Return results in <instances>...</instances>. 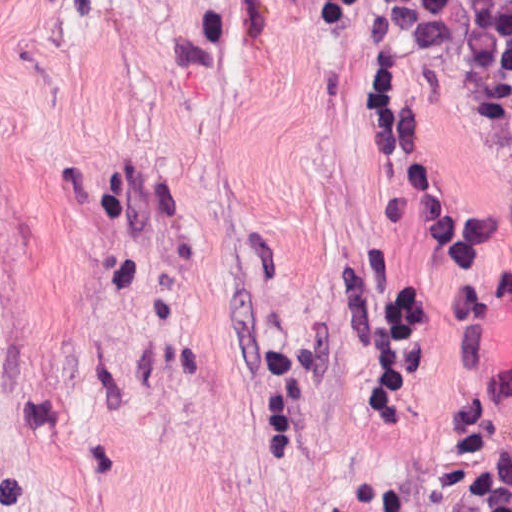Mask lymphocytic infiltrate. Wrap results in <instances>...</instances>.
Masks as SVG:
<instances>
[{"label": "lymphocytic infiltrate", "instance_id": "lymphocytic-infiltrate-1", "mask_svg": "<svg viewBox=\"0 0 512 512\" xmlns=\"http://www.w3.org/2000/svg\"><path fill=\"white\" fill-rule=\"evenodd\" d=\"M315 1V0H313ZM391 32L431 49L445 77L471 92L512 135V0H382ZM390 184L404 210L444 239L466 326V405L435 467L443 512H512V358L473 276L470 257L426 160L388 44L362 76ZM334 304L356 349L371 411L420 385L427 339L404 277L362 252L334 280ZM317 397V358L291 324L266 339L255 390V451L296 443Z\"/></svg>", "mask_w": 512, "mask_h": 512}]
</instances>
